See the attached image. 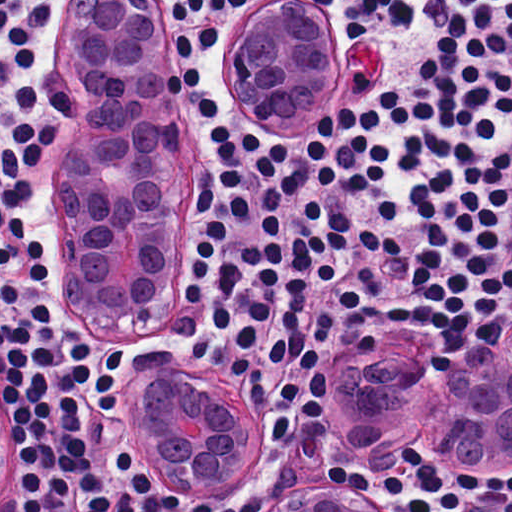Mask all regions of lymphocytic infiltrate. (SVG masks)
Here are the masks:
<instances>
[{
    "instance_id": "lymphocytic-infiltrate-1",
    "label": "lymphocytic infiltrate",
    "mask_w": 512,
    "mask_h": 512,
    "mask_svg": "<svg viewBox=\"0 0 512 512\" xmlns=\"http://www.w3.org/2000/svg\"><path fill=\"white\" fill-rule=\"evenodd\" d=\"M346 22L396 37L398 84L337 105L307 140V166L326 196L373 192L391 162L376 130L401 128L394 229L376 228L317 201L285 243L231 245L199 189V233L187 302L228 337L231 378L256 411L274 409L268 441L286 445L300 409L326 402L320 350L334 337L445 327L439 310L376 301V266L397 250L410 282L472 338L493 340L512 300V0H320ZM236 0H162L171 12L173 72L210 133L229 214L248 223L242 172L252 158L268 236L300 191L293 149L236 130L192 61L216 43ZM61 0H0V456L8 512H236L196 509L184 497L242 501L233 487L173 489L149 466L116 386L136 364L102 334L70 320L57 289L62 169L59 139L71 95L50 70L46 45ZM416 265L428 270L417 281ZM119 356L125 361L120 370ZM121 405V407H120ZM131 455L135 463L130 459ZM395 475H325L410 512H462L483 499L512 512V476L462 472L414 445Z\"/></svg>"
}]
</instances>
